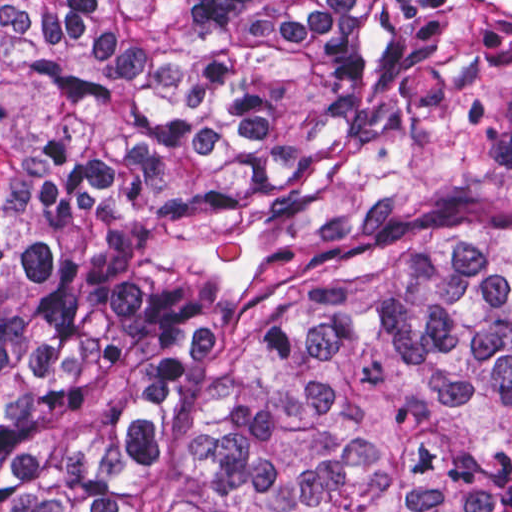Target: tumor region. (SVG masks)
Listing matches in <instances>:
<instances>
[{"label":"tumor region","instance_id":"obj_1","mask_svg":"<svg viewBox=\"0 0 512 512\" xmlns=\"http://www.w3.org/2000/svg\"><path fill=\"white\" fill-rule=\"evenodd\" d=\"M0 512H512V0H0Z\"/></svg>","mask_w":512,"mask_h":512}]
</instances>
